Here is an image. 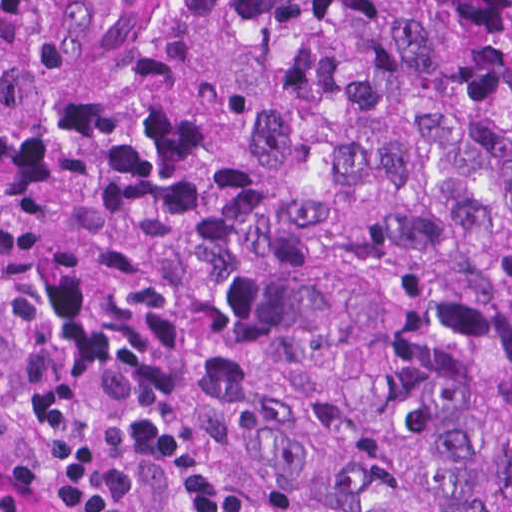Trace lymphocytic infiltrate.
I'll use <instances>...</instances> for the list:
<instances>
[{"label":"lymphocytic infiltrate","mask_w":512,"mask_h":512,"mask_svg":"<svg viewBox=\"0 0 512 512\" xmlns=\"http://www.w3.org/2000/svg\"><path fill=\"white\" fill-rule=\"evenodd\" d=\"M0 512H174L108 449L52 440L0 374Z\"/></svg>","instance_id":"1"}]
</instances>
